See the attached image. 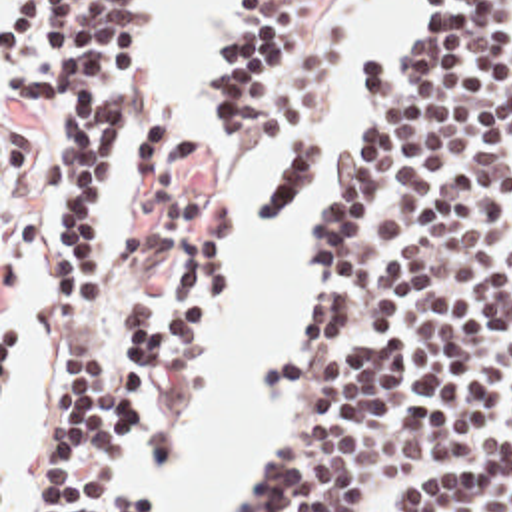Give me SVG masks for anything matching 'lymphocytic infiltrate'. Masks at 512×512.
Here are the masks:
<instances>
[{
    "label": "lymphocytic infiltrate",
    "instance_id": "obj_1",
    "mask_svg": "<svg viewBox=\"0 0 512 512\" xmlns=\"http://www.w3.org/2000/svg\"><path fill=\"white\" fill-rule=\"evenodd\" d=\"M353 0H238L202 70L214 148L274 138L264 242L323 144ZM407 0L415 40L391 74L359 68L349 160L327 158L329 226L276 458L228 512H512V6ZM2 100L42 128V188L76 192L56 232L58 332L24 512H160L124 492L182 450L160 398L224 328L228 258L186 240L212 156L148 108L138 0H10ZM136 186L134 240L170 260V296L106 280L108 188Z\"/></svg>",
    "mask_w": 512,
    "mask_h": 512
}]
</instances>
